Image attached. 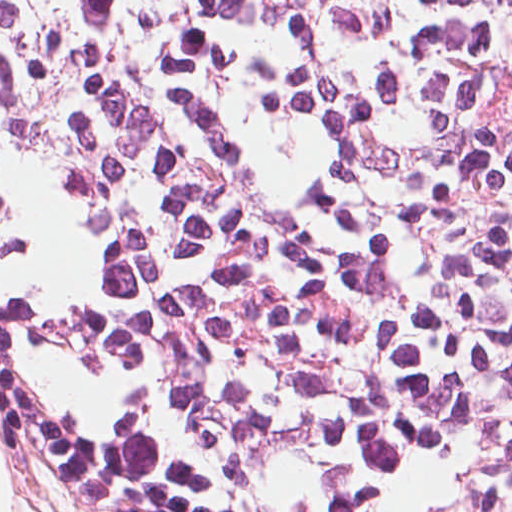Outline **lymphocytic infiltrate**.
Instances as JSON below:
<instances>
[{
	"label": "lymphocytic infiltrate",
	"instance_id": "lymphocytic-infiltrate-1",
	"mask_svg": "<svg viewBox=\"0 0 512 512\" xmlns=\"http://www.w3.org/2000/svg\"><path fill=\"white\" fill-rule=\"evenodd\" d=\"M0 427L80 512H512V0H0Z\"/></svg>",
	"mask_w": 512,
	"mask_h": 512
}]
</instances>
